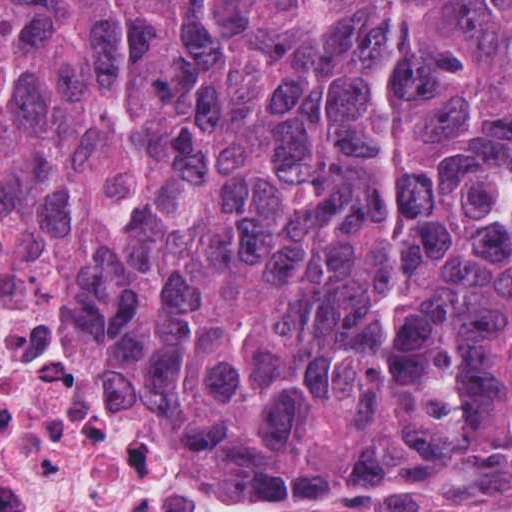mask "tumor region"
I'll return each instance as SVG.
<instances>
[{
	"instance_id": "tumor-region-1",
	"label": "tumor region",
	"mask_w": 512,
	"mask_h": 512,
	"mask_svg": "<svg viewBox=\"0 0 512 512\" xmlns=\"http://www.w3.org/2000/svg\"><path fill=\"white\" fill-rule=\"evenodd\" d=\"M0 244L209 483L510 454L512 0H0Z\"/></svg>"
}]
</instances>
